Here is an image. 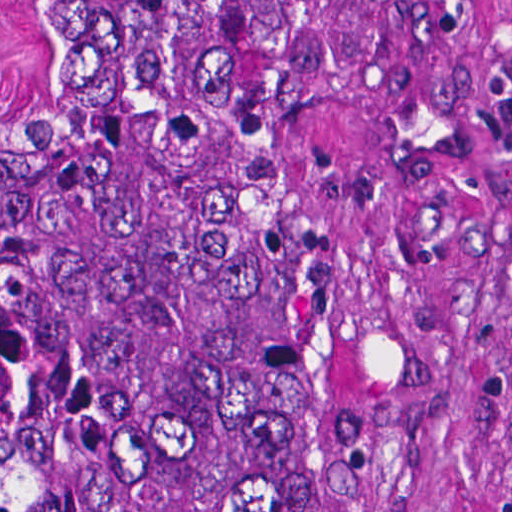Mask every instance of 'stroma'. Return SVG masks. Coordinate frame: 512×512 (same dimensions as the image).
<instances>
[{"label": "stroma", "instance_id": "35a3bbf8", "mask_svg": "<svg viewBox=\"0 0 512 512\" xmlns=\"http://www.w3.org/2000/svg\"><path fill=\"white\" fill-rule=\"evenodd\" d=\"M42 1H324L277 232L348 310L380 512H512V0H0V112Z\"/></svg>", "mask_w": 512, "mask_h": 512}]
</instances>
